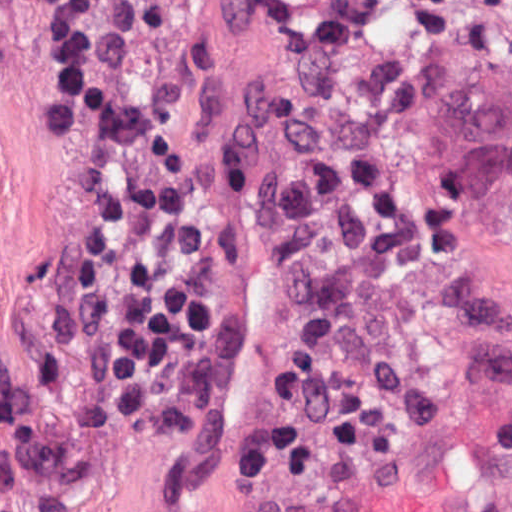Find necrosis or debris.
Masks as SVG:
<instances>
[{
  "label": "necrosis or debris",
  "mask_w": 512,
  "mask_h": 512,
  "mask_svg": "<svg viewBox=\"0 0 512 512\" xmlns=\"http://www.w3.org/2000/svg\"><path fill=\"white\" fill-rule=\"evenodd\" d=\"M209 1L97 0L92 76L170 93ZM238 2L204 156L318 303L236 448L287 487L512 382V0Z\"/></svg>",
  "instance_id": "1"
}]
</instances>
